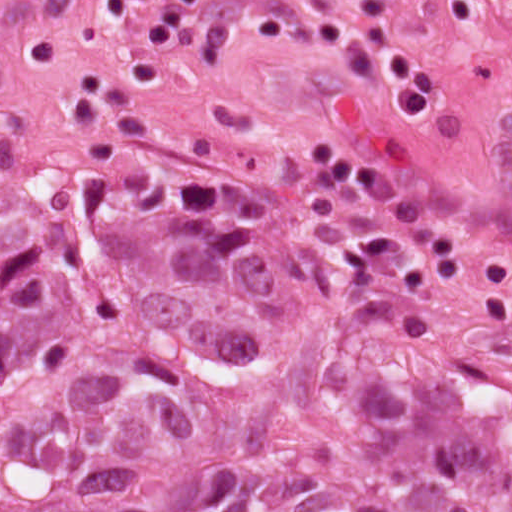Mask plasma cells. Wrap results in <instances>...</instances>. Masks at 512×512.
Here are the masks:
<instances>
[{"label":"plasma cells","mask_w":512,"mask_h":512,"mask_svg":"<svg viewBox=\"0 0 512 512\" xmlns=\"http://www.w3.org/2000/svg\"><path fill=\"white\" fill-rule=\"evenodd\" d=\"M201 7L208 0H180ZM395 0H358L357 11L372 54L387 67L386 105L397 120H421L436 104V77L394 39L390 18ZM512 85V60L508 65Z\"/></svg>","instance_id":"plasma-cells-1"}]
</instances>
